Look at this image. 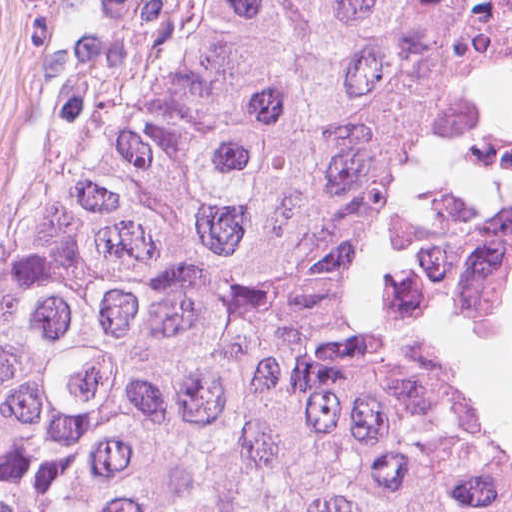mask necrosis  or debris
<instances>
[{
  "instance_id": "4bbe7bcc",
  "label": "necrosis or debris",
  "mask_w": 512,
  "mask_h": 512,
  "mask_svg": "<svg viewBox=\"0 0 512 512\" xmlns=\"http://www.w3.org/2000/svg\"><path fill=\"white\" fill-rule=\"evenodd\" d=\"M360 253L392 338L512 420V0H424L360 131Z\"/></svg>"
}]
</instances>
